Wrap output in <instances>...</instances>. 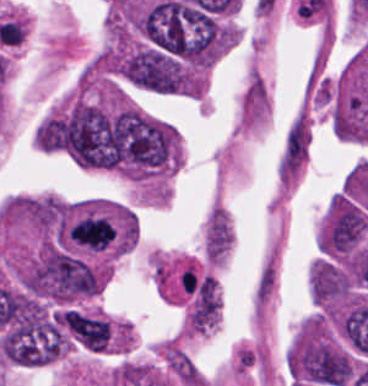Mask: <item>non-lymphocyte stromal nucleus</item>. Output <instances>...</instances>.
<instances>
[{
    "instance_id": "non-lymphocyte-stromal-nucleus-1",
    "label": "non-lymphocyte stromal nucleus",
    "mask_w": 368,
    "mask_h": 386,
    "mask_svg": "<svg viewBox=\"0 0 368 386\" xmlns=\"http://www.w3.org/2000/svg\"><path fill=\"white\" fill-rule=\"evenodd\" d=\"M310 137L309 122L304 115H300L290 126L284 151L283 160L288 167H300L306 157Z\"/></svg>"
},
{
    "instance_id": "non-lymphocyte-stromal-nucleus-2",
    "label": "non-lymphocyte stromal nucleus",
    "mask_w": 368,
    "mask_h": 386,
    "mask_svg": "<svg viewBox=\"0 0 368 386\" xmlns=\"http://www.w3.org/2000/svg\"><path fill=\"white\" fill-rule=\"evenodd\" d=\"M165 361L176 379L186 384H198L196 365L185 352L171 347L166 348Z\"/></svg>"
}]
</instances>
